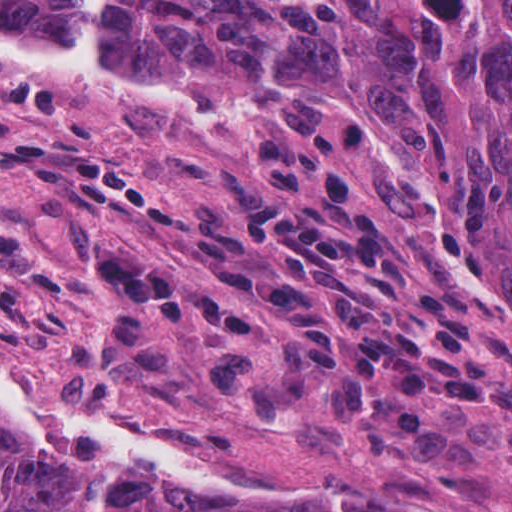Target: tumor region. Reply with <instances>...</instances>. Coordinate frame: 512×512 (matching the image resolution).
I'll return each instance as SVG.
<instances>
[{
	"label": "tumor region",
	"instance_id": "1",
	"mask_svg": "<svg viewBox=\"0 0 512 512\" xmlns=\"http://www.w3.org/2000/svg\"><path fill=\"white\" fill-rule=\"evenodd\" d=\"M85 1L0 0V21L68 27ZM113 39L189 77L362 100L453 174L512 297V0H117ZM0 512L352 511L218 499L0 441Z\"/></svg>",
	"mask_w": 512,
	"mask_h": 512
}]
</instances>
